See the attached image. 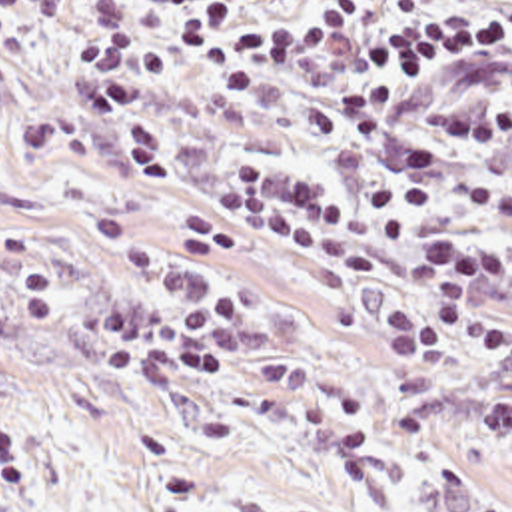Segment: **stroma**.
<instances>
[{"label":"stroma","instance_id":"35a3bbf8","mask_svg":"<svg viewBox=\"0 0 512 512\" xmlns=\"http://www.w3.org/2000/svg\"><path fill=\"white\" fill-rule=\"evenodd\" d=\"M494 2V0H426ZM135 32L167 50L147 98L167 176L141 186L113 124L81 88L83 0H41L0 42V214L39 224L67 286V318L29 324L17 264L0 284V421L29 459L19 499L0 512H512V449L486 445L478 399L512 377L476 351L414 369L378 338L410 296L402 250L361 228L367 276H333L273 240L227 222L213 184L239 154H263L337 194L396 170L408 142L454 154L446 216L482 232L496 216L466 204L484 180L512 190V138L474 148L432 120L446 106H512V74L460 64L402 102L384 158L361 162L315 142L287 100L223 98L161 32L143 0H123ZM99 202L127 210L155 242L175 208L207 212L241 240L257 270L265 324L225 369L197 383H135L79 353V310L117 282L87 236ZM512 318V290L488 302Z\"/></svg>","mask_w":512,"mask_h":512}]
</instances>
